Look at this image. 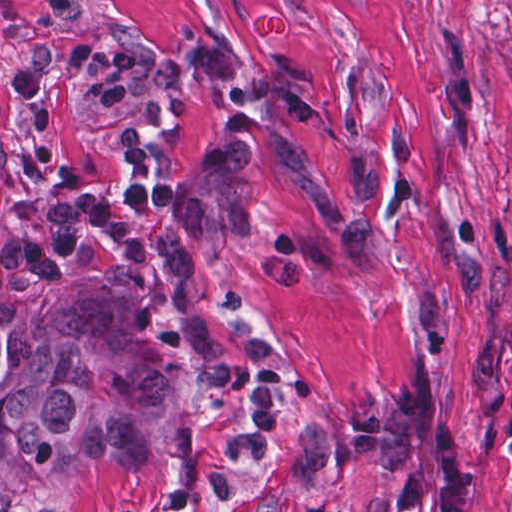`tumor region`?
Here are the masks:
<instances>
[{"label": "tumor region", "mask_w": 512, "mask_h": 512, "mask_svg": "<svg viewBox=\"0 0 512 512\" xmlns=\"http://www.w3.org/2000/svg\"><path fill=\"white\" fill-rule=\"evenodd\" d=\"M512 124V40L499 54ZM175 374L141 340L137 295L30 276L0 259V510L75 469L99 473L153 449ZM373 441L416 471L402 512H476L462 473V409L424 371L323 410L295 433V486Z\"/></svg>", "instance_id": "obj_1"}]
</instances>
